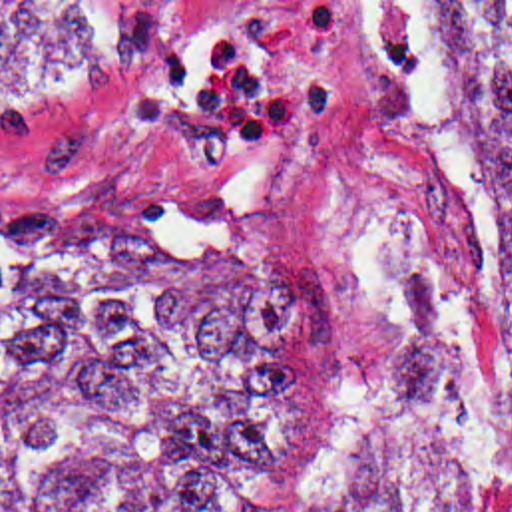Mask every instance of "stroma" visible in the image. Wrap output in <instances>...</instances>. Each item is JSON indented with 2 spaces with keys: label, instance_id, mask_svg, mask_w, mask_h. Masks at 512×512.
Returning <instances> with one entry per match:
<instances>
[{
  "label": "stroma",
  "instance_id": "1",
  "mask_svg": "<svg viewBox=\"0 0 512 512\" xmlns=\"http://www.w3.org/2000/svg\"><path fill=\"white\" fill-rule=\"evenodd\" d=\"M179 2L137 60L48 92H0V199L111 215L143 187L219 197L336 309V448L291 512H316L386 370L412 271L450 283L478 354L494 307L482 153L430 66L412 2Z\"/></svg>",
  "mask_w": 512,
  "mask_h": 512
}]
</instances>
